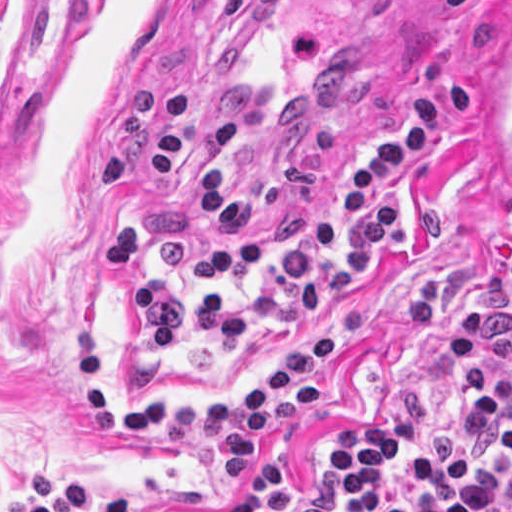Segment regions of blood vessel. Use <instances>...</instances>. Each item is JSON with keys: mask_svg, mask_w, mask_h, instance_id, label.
Wrapping results in <instances>:
<instances>
[{"mask_svg": "<svg viewBox=\"0 0 512 512\" xmlns=\"http://www.w3.org/2000/svg\"><path fill=\"white\" fill-rule=\"evenodd\" d=\"M472 125L483 159L512 202V12L499 28Z\"/></svg>", "mask_w": 512, "mask_h": 512, "instance_id": "1", "label": "blood vessel"}]
</instances>
